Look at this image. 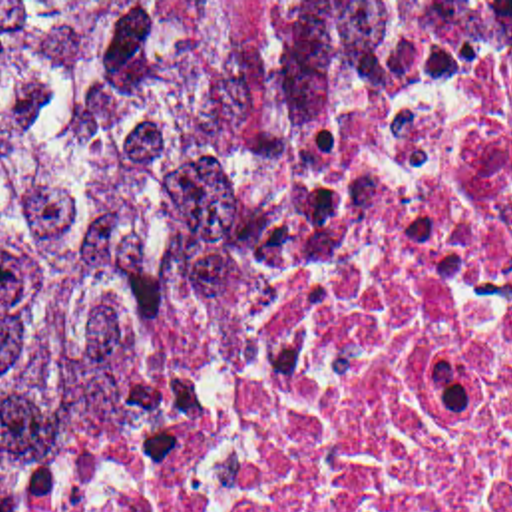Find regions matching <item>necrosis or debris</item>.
Returning a JSON list of instances; mask_svg holds the SVG:
<instances>
[{
    "mask_svg": "<svg viewBox=\"0 0 512 512\" xmlns=\"http://www.w3.org/2000/svg\"><path fill=\"white\" fill-rule=\"evenodd\" d=\"M0 512H512V34L330 147Z\"/></svg>",
    "mask_w": 512,
    "mask_h": 512,
    "instance_id": "1",
    "label": "necrosis or debris"
}]
</instances>
